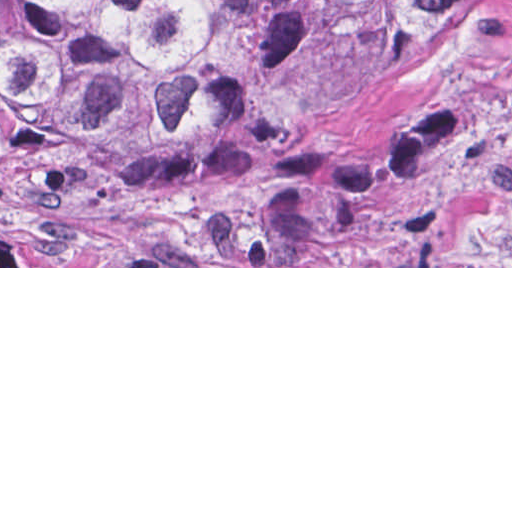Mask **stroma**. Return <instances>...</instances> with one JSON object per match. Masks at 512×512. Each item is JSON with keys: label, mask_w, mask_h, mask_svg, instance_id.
Segmentation results:
<instances>
[{"label": "stroma", "mask_w": 512, "mask_h": 512, "mask_svg": "<svg viewBox=\"0 0 512 512\" xmlns=\"http://www.w3.org/2000/svg\"><path fill=\"white\" fill-rule=\"evenodd\" d=\"M324 142L321 225L255 266L0 268H512V0H449Z\"/></svg>", "instance_id": "35a3bbf8"}]
</instances>
